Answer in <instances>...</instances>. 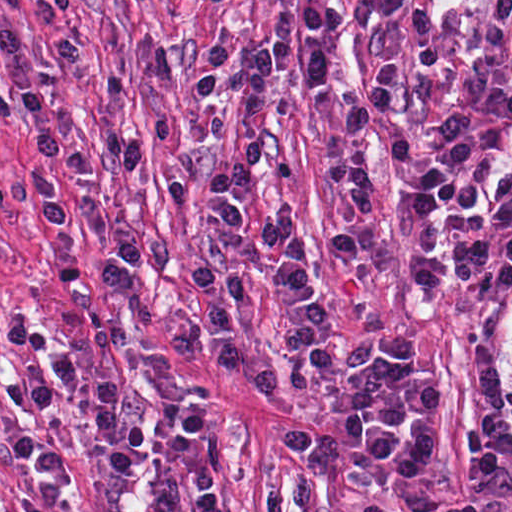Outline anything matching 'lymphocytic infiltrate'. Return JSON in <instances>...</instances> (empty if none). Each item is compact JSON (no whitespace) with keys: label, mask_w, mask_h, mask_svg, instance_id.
Listing matches in <instances>:
<instances>
[{"label":"lymphocytic infiltrate","mask_w":512,"mask_h":512,"mask_svg":"<svg viewBox=\"0 0 512 512\" xmlns=\"http://www.w3.org/2000/svg\"><path fill=\"white\" fill-rule=\"evenodd\" d=\"M23 37L14 22L0 20V60L22 109L25 148L36 174L26 181L0 172V213L5 202L33 203L50 232L55 281L61 286L128 291L137 275V245L130 239H121L90 274L81 276L72 261L70 225L51 175H79L90 166L82 152L60 143L55 121L28 64ZM7 241L0 223V250ZM5 333L11 345L32 361L30 371L0 383L12 403L29 408L26 423L10 437L15 458L36 471L24 512H55L69 476L68 454L54 432L56 400L67 390L76 392L86 406L102 464L125 481L136 477L140 457L158 432L181 430L179 468L155 490L159 512H173L185 505H192L193 512H227L221 440L196 399L158 397L146 412L134 414L123 379L89 376L73 354L27 320L8 321Z\"/></svg>","instance_id":"1"}]
</instances>
